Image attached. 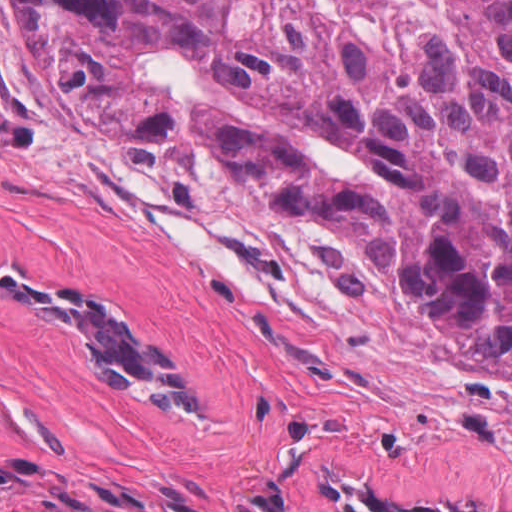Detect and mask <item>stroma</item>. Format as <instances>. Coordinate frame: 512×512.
I'll list each match as a JSON object with an SVG mask.
<instances>
[{"instance_id": "obj_1", "label": "stroma", "mask_w": 512, "mask_h": 512, "mask_svg": "<svg viewBox=\"0 0 512 512\" xmlns=\"http://www.w3.org/2000/svg\"><path fill=\"white\" fill-rule=\"evenodd\" d=\"M0 258L127 300L238 400L233 430L149 422L0 297V512H337L321 471L512 512V380L385 283L352 229L250 192L196 137L74 107L0 0Z\"/></svg>"}]
</instances>
